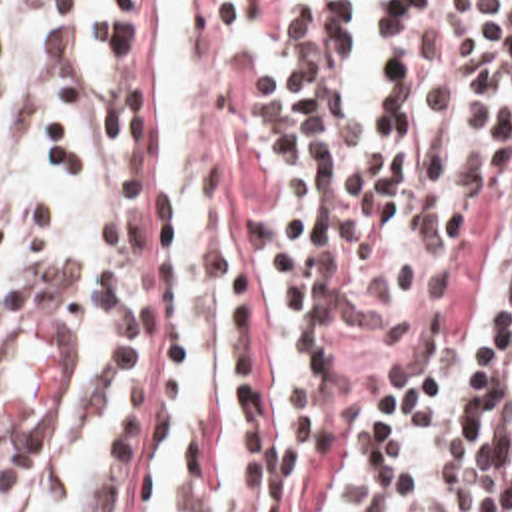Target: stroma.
<instances>
[{"instance_id":"obj_1","label":"stroma","mask_w":512,"mask_h":512,"mask_svg":"<svg viewBox=\"0 0 512 512\" xmlns=\"http://www.w3.org/2000/svg\"><path fill=\"white\" fill-rule=\"evenodd\" d=\"M400 0H194L202 44V92L234 64L310 46L382 14ZM166 0H120V84L158 92V38Z\"/></svg>"}]
</instances>
